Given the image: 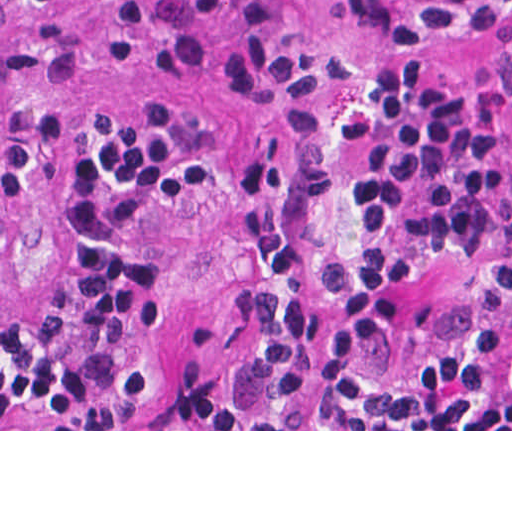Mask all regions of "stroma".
<instances>
[{
    "instance_id": "1",
    "label": "stroma",
    "mask_w": 512,
    "mask_h": 512,
    "mask_svg": "<svg viewBox=\"0 0 512 512\" xmlns=\"http://www.w3.org/2000/svg\"><path fill=\"white\" fill-rule=\"evenodd\" d=\"M310 20L333 0H282ZM190 0H147L138 17L103 0L55 8L0 0V90L21 118L24 156L5 196L0 302L36 313L64 280V189L88 127L137 105L179 124L200 204L162 238V351L181 354L212 332L237 298L230 223L252 157L256 123L240 116L219 52L192 75L171 68L167 35ZM437 52L419 59L361 53L370 83L428 77L445 86L474 138L486 195L463 246L423 254L366 213L359 140L345 144L348 181L338 242L347 256L389 259L405 296L383 341V363H429L456 320L512 269V24H489L477 0H419ZM0 431H512V403L487 415L398 429H0Z\"/></svg>"
}]
</instances>
